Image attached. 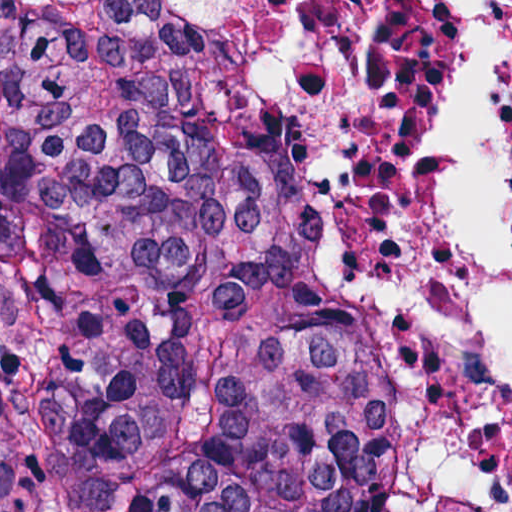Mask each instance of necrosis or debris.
<instances>
[{
    "mask_svg": "<svg viewBox=\"0 0 512 512\" xmlns=\"http://www.w3.org/2000/svg\"><path fill=\"white\" fill-rule=\"evenodd\" d=\"M477 6L501 23L478 213L512 264L497 214V123L512 100L509 1H352L348 20V214L422 353L435 512H512V342L471 273L455 118L460 29Z\"/></svg>",
    "mask_w": 512,
    "mask_h": 512,
    "instance_id": "obj_1",
    "label": "necrosis or debris"
}]
</instances>
